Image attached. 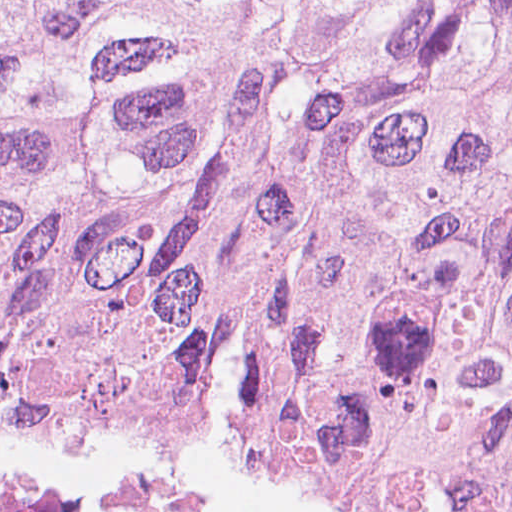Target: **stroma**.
<instances>
[{
	"mask_svg": "<svg viewBox=\"0 0 512 512\" xmlns=\"http://www.w3.org/2000/svg\"><path fill=\"white\" fill-rule=\"evenodd\" d=\"M506 461L512 458L362 463L274 441H0V467L160 475L208 512H367L288 476Z\"/></svg>",
	"mask_w": 512,
	"mask_h": 512,
	"instance_id": "1",
	"label": "stroma"
}]
</instances>
